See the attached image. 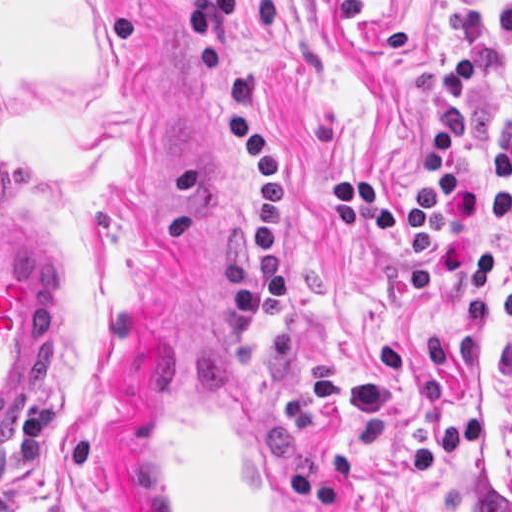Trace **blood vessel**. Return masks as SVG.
I'll return each mask as SVG.
<instances>
[{"label": "blood vessel", "mask_w": 512, "mask_h": 512, "mask_svg": "<svg viewBox=\"0 0 512 512\" xmlns=\"http://www.w3.org/2000/svg\"><path fill=\"white\" fill-rule=\"evenodd\" d=\"M26 222L0 215V442L39 395L65 308ZM199 350L165 352L141 376L138 512H320L255 382Z\"/></svg>", "instance_id": "obj_1"}]
</instances>
